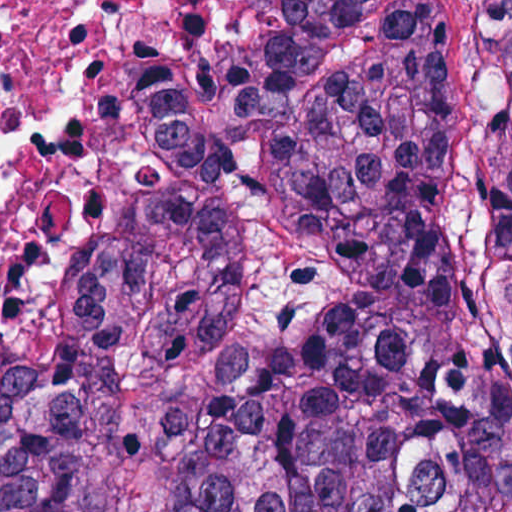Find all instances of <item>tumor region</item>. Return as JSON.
Instances as JSON below:
<instances>
[{"instance_id": "e687c5a6", "label": "tumor region", "mask_w": 512, "mask_h": 512, "mask_svg": "<svg viewBox=\"0 0 512 512\" xmlns=\"http://www.w3.org/2000/svg\"><path fill=\"white\" fill-rule=\"evenodd\" d=\"M94 35L147 168L0 420V512H512V1Z\"/></svg>"}]
</instances>
